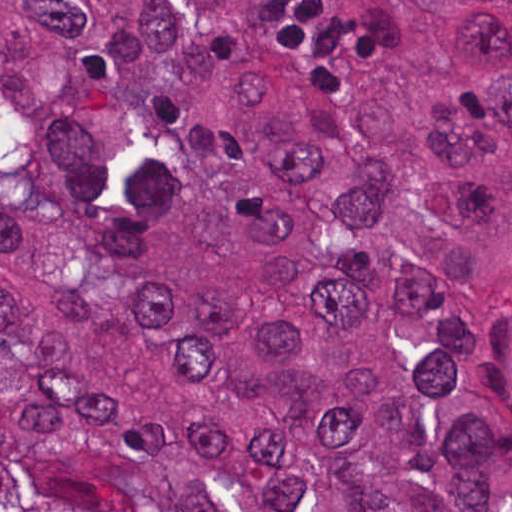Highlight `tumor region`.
Wrapping results in <instances>:
<instances>
[{"label": "tumor region", "instance_id": "obj_1", "mask_svg": "<svg viewBox=\"0 0 512 512\" xmlns=\"http://www.w3.org/2000/svg\"><path fill=\"white\" fill-rule=\"evenodd\" d=\"M0 512H512V1H0Z\"/></svg>", "mask_w": 512, "mask_h": 512}]
</instances>
